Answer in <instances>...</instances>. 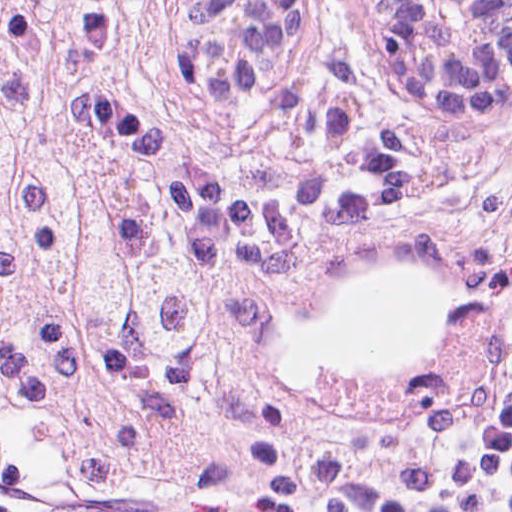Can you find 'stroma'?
<instances>
[{
  "label": "stroma",
  "instance_id": "stroma-1",
  "mask_svg": "<svg viewBox=\"0 0 512 512\" xmlns=\"http://www.w3.org/2000/svg\"><path fill=\"white\" fill-rule=\"evenodd\" d=\"M142 68L79 90L85 128L138 169L184 246L268 301L264 338L370 266L422 270L440 311L429 364L375 381H268L251 411L157 480L75 491L39 425L0 420V512H384L402 414L461 347L507 317L512 241L469 207L461 159L496 121L423 114L379 80L350 0H317L249 111L276 177L207 171L140 108Z\"/></svg>",
  "mask_w": 512,
  "mask_h": 512
}]
</instances>
